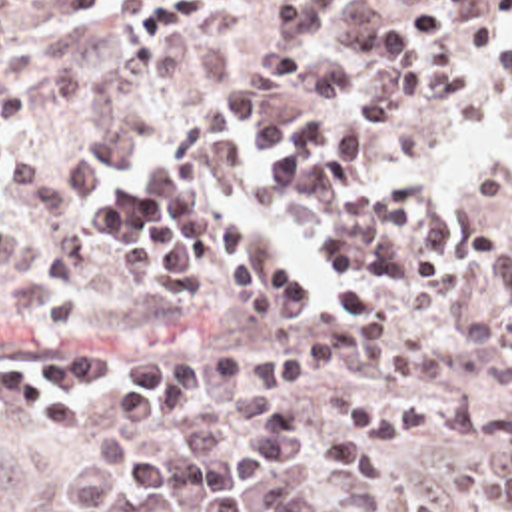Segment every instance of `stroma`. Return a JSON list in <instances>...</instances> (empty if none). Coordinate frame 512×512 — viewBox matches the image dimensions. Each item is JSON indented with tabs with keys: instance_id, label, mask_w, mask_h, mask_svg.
Listing matches in <instances>:
<instances>
[{
	"instance_id": "obj_1",
	"label": "stroma",
	"mask_w": 512,
	"mask_h": 512,
	"mask_svg": "<svg viewBox=\"0 0 512 512\" xmlns=\"http://www.w3.org/2000/svg\"><path fill=\"white\" fill-rule=\"evenodd\" d=\"M285 0H237L157 50H131L125 24L147 10L123 0H91L75 20L47 28H1L0 98L29 82L39 108V142L69 144L111 122L147 116L201 126L231 150V186L211 206L241 218L253 248L281 250L315 288L307 316L255 318L225 272L211 268V298L181 302L145 286L121 266V250L95 242L79 272H61V248L31 200L0 186V244L25 236L37 244V278L0 300V390L15 374L69 360L91 346L133 356L169 352H281L307 346L337 316L329 296L343 282L327 274L319 246L327 218L291 192H267L263 170L277 158L243 154L235 126L195 70L201 40L271 36ZM472 60L470 92L446 102L402 108L394 128L362 146L366 174L384 190L402 178L424 184L416 220L442 214L456 226H500L502 246L478 268L408 296L386 310L378 350L321 364L311 388H247L203 382L165 424H111L109 396L121 378L81 388L73 424H45L0 394V480L15 484V512H85L51 490L69 470L107 456H185L183 426L215 424L227 448L249 428L309 426L344 438L333 404L352 388L384 402L408 396H470L512 408V82L492 60L454 38ZM346 64L323 46L291 86L251 74L267 116L309 124L305 74ZM364 92L394 84L380 62L350 66ZM331 506L360 512H512L508 448L488 440H406L384 486L325 474ZM165 512H199L189 502Z\"/></svg>"
}]
</instances>
